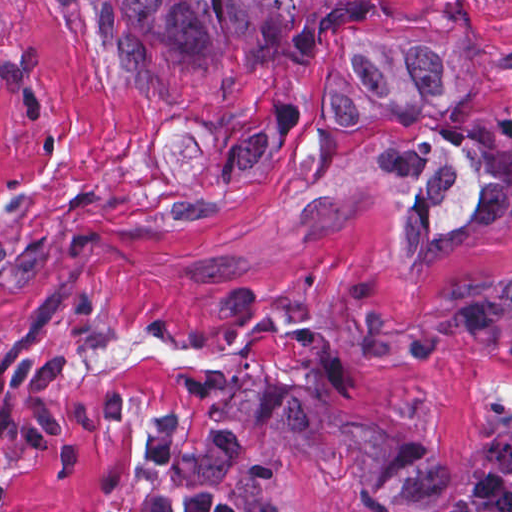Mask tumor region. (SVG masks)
Segmentation results:
<instances>
[{
  "label": "tumor region",
  "instance_id": "tumor-region-1",
  "mask_svg": "<svg viewBox=\"0 0 512 512\" xmlns=\"http://www.w3.org/2000/svg\"><path fill=\"white\" fill-rule=\"evenodd\" d=\"M193 54L252 44L283 55L330 51L316 100L333 112L393 115L476 97L486 60L453 23L390 25L362 0H123ZM469 215L512 217V110L407 148L391 219L403 265L426 267L455 244ZM409 351H494L512 344V270L462 292L422 320L380 333Z\"/></svg>",
  "mask_w": 512,
  "mask_h": 512
}]
</instances>
